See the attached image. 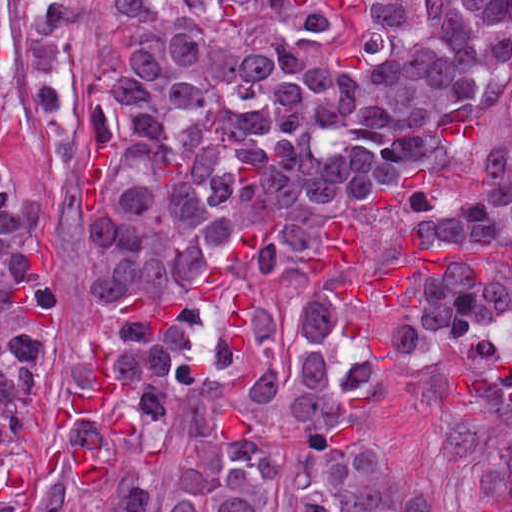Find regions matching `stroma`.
Segmentation results:
<instances>
[{"label": "stroma", "instance_id": "obj_1", "mask_svg": "<svg viewBox=\"0 0 512 512\" xmlns=\"http://www.w3.org/2000/svg\"><path fill=\"white\" fill-rule=\"evenodd\" d=\"M0 11L13 88L12 115L0 136V185L11 213L32 197L42 202L43 227L56 255L53 353L39 402L22 427L24 498L17 512H110L54 447L49 410L80 369L87 329L94 264L74 201L93 136V76L126 43L111 0H86L73 17V104L62 123L45 127L21 0H1ZM495 312H512V264L494 302L468 313L428 354L394 364L371 389V408L393 459L440 509L512 477V367L464 357L477 323ZM191 442L189 429L170 432L141 512H173L177 472Z\"/></svg>", "mask_w": 512, "mask_h": 512}]
</instances>
